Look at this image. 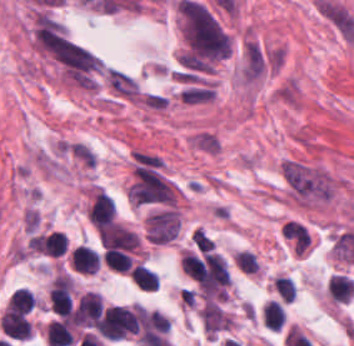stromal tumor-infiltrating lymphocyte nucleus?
<instances>
[{
    "instance_id": "abfb95fc",
    "label": "stromal tumor-infiltrating lymphocyte nucleus",
    "mask_w": 354,
    "mask_h": 346,
    "mask_svg": "<svg viewBox=\"0 0 354 346\" xmlns=\"http://www.w3.org/2000/svg\"><path fill=\"white\" fill-rule=\"evenodd\" d=\"M0 325L6 336L16 340H26L30 337L29 324L23 315L2 312Z\"/></svg>"
},
{
    "instance_id": "9ea309e8",
    "label": "stromal tumor-infiltrating lymphocyte nucleus",
    "mask_w": 354,
    "mask_h": 346,
    "mask_svg": "<svg viewBox=\"0 0 354 346\" xmlns=\"http://www.w3.org/2000/svg\"><path fill=\"white\" fill-rule=\"evenodd\" d=\"M46 343L48 346L71 345L74 336L66 321L55 320L45 328Z\"/></svg>"
},
{
    "instance_id": "4c9ddf68",
    "label": "stromal tumor-infiltrating lymphocyte nucleus",
    "mask_w": 354,
    "mask_h": 346,
    "mask_svg": "<svg viewBox=\"0 0 354 346\" xmlns=\"http://www.w3.org/2000/svg\"><path fill=\"white\" fill-rule=\"evenodd\" d=\"M273 287L284 302L289 303L295 298V285L293 280L283 275H275Z\"/></svg>"
},
{
    "instance_id": "2761f720",
    "label": "stromal tumor-infiltrating lymphocyte nucleus",
    "mask_w": 354,
    "mask_h": 346,
    "mask_svg": "<svg viewBox=\"0 0 354 346\" xmlns=\"http://www.w3.org/2000/svg\"><path fill=\"white\" fill-rule=\"evenodd\" d=\"M238 270L243 273H256L258 260L254 252L239 250L233 258Z\"/></svg>"
},
{
    "instance_id": "52c7bb5b",
    "label": "stromal tumor-infiltrating lymphocyte nucleus",
    "mask_w": 354,
    "mask_h": 346,
    "mask_svg": "<svg viewBox=\"0 0 354 346\" xmlns=\"http://www.w3.org/2000/svg\"><path fill=\"white\" fill-rule=\"evenodd\" d=\"M98 239L105 247L134 251L139 243L137 235L129 228L110 223L97 233Z\"/></svg>"
},
{
    "instance_id": "4245b91a",
    "label": "stromal tumor-infiltrating lymphocyte nucleus",
    "mask_w": 354,
    "mask_h": 346,
    "mask_svg": "<svg viewBox=\"0 0 354 346\" xmlns=\"http://www.w3.org/2000/svg\"><path fill=\"white\" fill-rule=\"evenodd\" d=\"M180 268L184 274L199 282L203 263L194 253L183 250L180 256Z\"/></svg>"
},
{
    "instance_id": "bc302bb0",
    "label": "stromal tumor-infiltrating lymphocyte nucleus",
    "mask_w": 354,
    "mask_h": 346,
    "mask_svg": "<svg viewBox=\"0 0 354 346\" xmlns=\"http://www.w3.org/2000/svg\"><path fill=\"white\" fill-rule=\"evenodd\" d=\"M115 215V203L101 188H94L86 209L89 223L96 229L110 224Z\"/></svg>"
},
{
    "instance_id": "4803ca6d",
    "label": "stromal tumor-infiltrating lymphocyte nucleus",
    "mask_w": 354,
    "mask_h": 346,
    "mask_svg": "<svg viewBox=\"0 0 354 346\" xmlns=\"http://www.w3.org/2000/svg\"><path fill=\"white\" fill-rule=\"evenodd\" d=\"M131 282L138 288L145 291H156L157 277L142 265L135 264L128 272Z\"/></svg>"
},
{
    "instance_id": "2a367800",
    "label": "stromal tumor-infiltrating lymphocyte nucleus",
    "mask_w": 354,
    "mask_h": 346,
    "mask_svg": "<svg viewBox=\"0 0 354 346\" xmlns=\"http://www.w3.org/2000/svg\"><path fill=\"white\" fill-rule=\"evenodd\" d=\"M101 261L114 272L127 273L131 266L129 254L114 247H106Z\"/></svg>"
},
{
    "instance_id": "4f13568d",
    "label": "stromal tumor-infiltrating lymphocyte nucleus",
    "mask_w": 354,
    "mask_h": 346,
    "mask_svg": "<svg viewBox=\"0 0 354 346\" xmlns=\"http://www.w3.org/2000/svg\"><path fill=\"white\" fill-rule=\"evenodd\" d=\"M260 315L262 325L270 331H279L285 320L284 310L280 302L275 300H268L264 303Z\"/></svg>"
},
{
    "instance_id": "3290ff9b",
    "label": "stromal tumor-infiltrating lymphocyte nucleus",
    "mask_w": 354,
    "mask_h": 346,
    "mask_svg": "<svg viewBox=\"0 0 354 346\" xmlns=\"http://www.w3.org/2000/svg\"><path fill=\"white\" fill-rule=\"evenodd\" d=\"M326 292L329 299L348 303L354 292V282L345 275L332 273L327 280Z\"/></svg>"
},
{
    "instance_id": "f3e2335f",
    "label": "stromal tumor-infiltrating lymphocyte nucleus",
    "mask_w": 354,
    "mask_h": 346,
    "mask_svg": "<svg viewBox=\"0 0 354 346\" xmlns=\"http://www.w3.org/2000/svg\"><path fill=\"white\" fill-rule=\"evenodd\" d=\"M35 306V300L27 288L17 290L6 303L5 316L16 317L27 313Z\"/></svg>"
}]
</instances>
